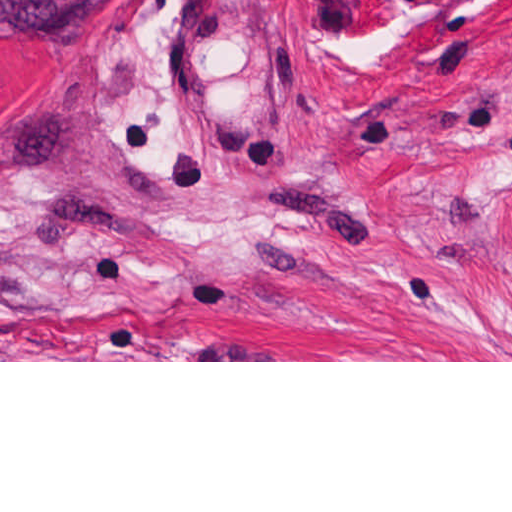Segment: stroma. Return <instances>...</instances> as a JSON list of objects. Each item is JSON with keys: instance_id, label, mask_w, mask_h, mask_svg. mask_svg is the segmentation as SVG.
<instances>
[{"instance_id": "35a3bbf8", "label": "stroma", "mask_w": 512, "mask_h": 512, "mask_svg": "<svg viewBox=\"0 0 512 512\" xmlns=\"http://www.w3.org/2000/svg\"><path fill=\"white\" fill-rule=\"evenodd\" d=\"M0 362H512V0L0 36Z\"/></svg>"}]
</instances>
